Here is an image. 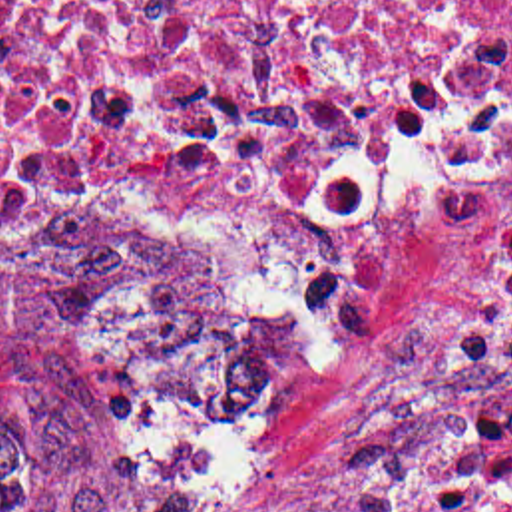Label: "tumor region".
<instances>
[{"instance_id":"tumor-region-1","label":"tumor region","mask_w":512,"mask_h":512,"mask_svg":"<svg viewBox=\"0 0 512 512\" xmlns=\"http://www.w3.org/2000/svg\"><path fill=\"white\" fill-rule=\"evenodd\" d=\"M47 290L173 430L181 490L135 508H57L0 480V512H240L278 474L294 410V332L205 241L91 229Z\"/></svg>"}]
</instances>
